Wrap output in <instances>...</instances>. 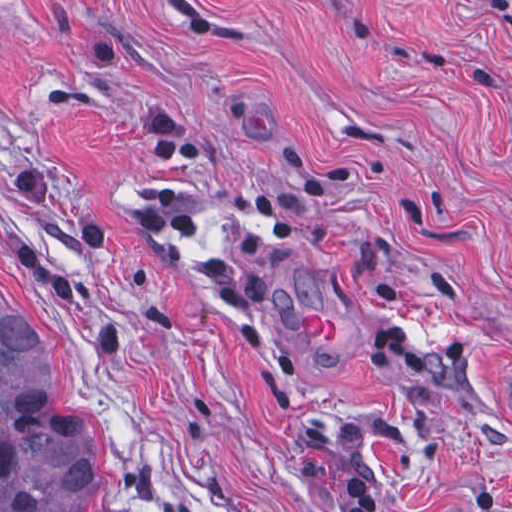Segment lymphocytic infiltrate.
Returning a JSON list of instances; mask_svg holds the SVG:
<instances>
[{
    "instance_id": "1",
    "label": "lymphocytic infiltrate",
    "mask_w": 512,
    "mask_h": 512,
    "mask_svg": "<svg viewBox=\"0 0 512 512\" xmlns=\"http://www.w3.org/2000/svg\"><path fill=\"white\" fill-rule=\"evenodd\" d=\"M344 512H388L384 494L373 484H354Z\"/></svg>"
}]
</instances>
